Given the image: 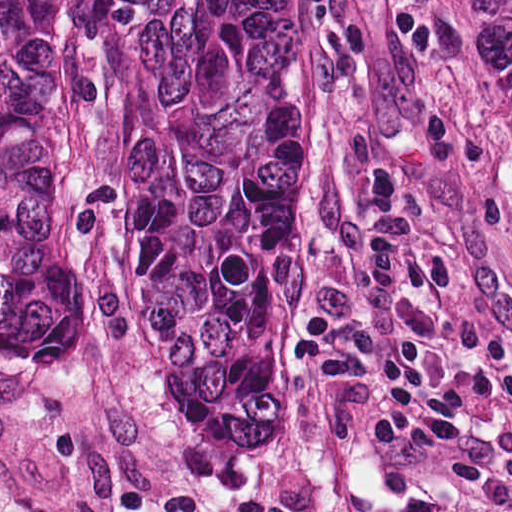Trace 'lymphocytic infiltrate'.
<instances>
[{
	"label": "lymphocytic infiltrate",
	"mask_w": 512,
	"mask_h": 512,
	"mask_svg": "<svg viewBox=\"0 0 512 512\" xmlns=\"http://www.w3.org/2000/svg\"><path fill=\"white\" fill-rule=\"evenodd\" d=\"M364 194L371 218L337 226L333 238L356 288L349 311L344 321L314 311L301 318L288 377L296 386L331 392L369 364L370 457L425 463L455 485L482 487L484 474L466 453L458 389L437 378L424 344L397 327V295L417 259L400 168L379 160L366 175Z\"/></svg>",
	"instance_id": "f902f5d3"
}]
</instances>
